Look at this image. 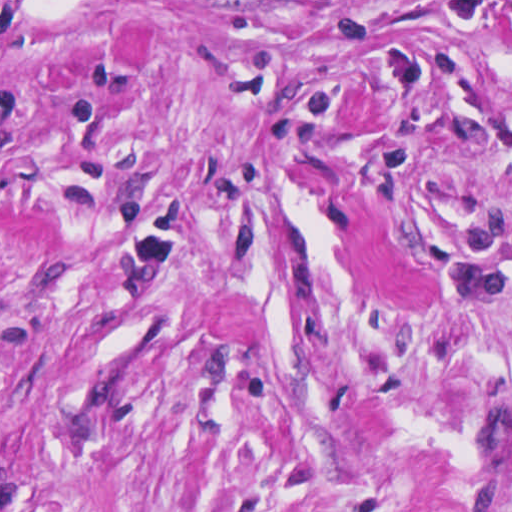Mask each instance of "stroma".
<instances>
[{"mask_svg": "<svg viewBox=\"0 0 512 512\" xmlns=\"http://www.w3.org/2000/svg\"><path fill=\"white\" fill-rule=\"evenodd\" d=\"M0 512H512V0H0Z\"/></svg>", "mask_w": 512, "mask_h": 512, "instance_id": "35a3bbf8", "label": "stroma"}]
</instances>
